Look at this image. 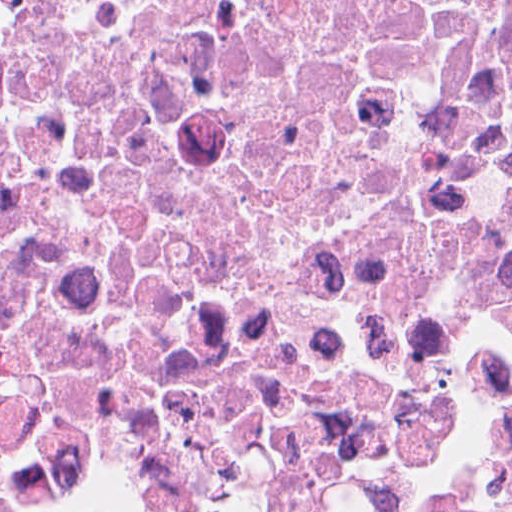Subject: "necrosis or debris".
<instances>
[{"mask_svg":"<svg viewBox=\"0 0 512 512\" xmlns=\"http://www.w3.org/2000/svg\"><path fill=\"white\" fill-rule=\"evenodd\" d=\"M511 441L512 0H0V477L461 512Z\"/></svg>","mask_w":512,"mask_h":512,"instance_id":"1","label":"necrosis or debris"}]
</instances>
